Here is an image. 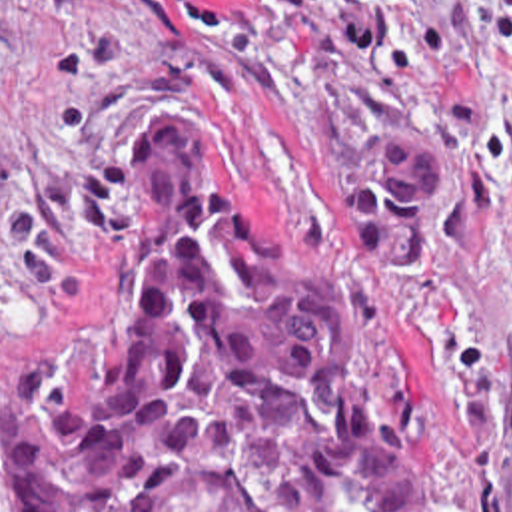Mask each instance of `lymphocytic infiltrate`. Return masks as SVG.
Segmentation results:
<instances>
[{
  "mask_svg": "<svg viewBox=\"0 0 512 512\" xmlns=\"http://www.w3.org/2000/svg\"><path fill=\"white\" fill-rule=\"evenodd\" d=\"M465 1L467 7L429 13L407 27L389 0H365L359 13L339 21L329 35L337 55L347 61H363L381 45V57L395 79H413L423 63L463 55L493 35L509 53L512 0Z\"/></svg>",
  "mask_w": 512,
  "mask_h": 512,
  "instance_id": "1",
  "label": "lymphocytic infiltrate"
}]
</instances>
